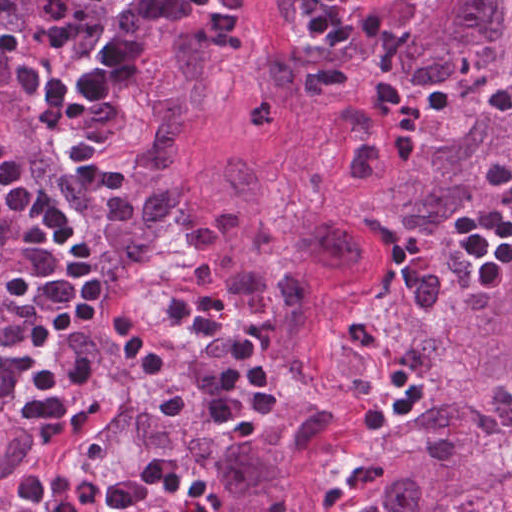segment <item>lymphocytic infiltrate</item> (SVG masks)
<instances>
[{
	"label": "lymphocytic infiltrate",
	"mask_w": 512,
	"mask_h": 512,
	"mask_svg": "<svg viewBox=\"0 0 512 512\" xmlns=\"http://www.w3.org/2000/svg\"><path fill=\"white\" fill-rule=\"evenodd\" d=\"M371 0H312L309 39L347 48L354 24ZM471 262L473 282L482 295L498 297L512 260V199L501 200L459 217ZM20 239L44 245L55 257L63 288L97 316L154 369L164 367V349L108 283L97 256L54 197L28 198L17 224ZM176 320L216 340L224 349L218 389L220 422L237 437H257L282 403V379L264 346L225 315L220 298L195 281L175 306ZM386 379L392 392L365 409L361 428L378 431L410 421L422 406L415 379L397 363Z\"/></svg>",
	"instance_id": "f902f5d3"
}]
</instances>
